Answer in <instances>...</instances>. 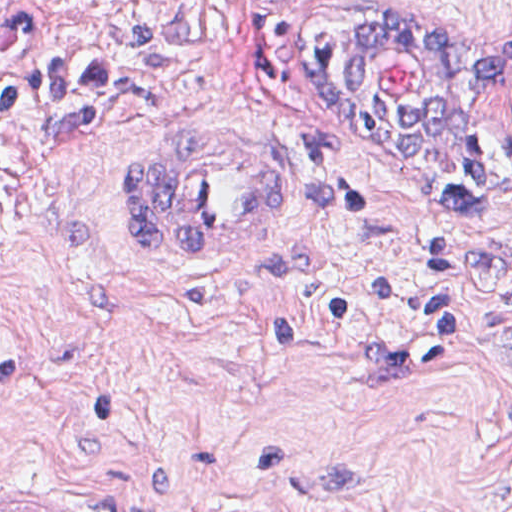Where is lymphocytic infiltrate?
<instances>
[{
  "label": "lymphocytic infiltrate",
  "mask_w": 512,
  "mask_h": 512,
  "mask_svg": "<svg viewBox=\"0 0 512 512\" xmlns=\"http://www.w3.org/2000/svg\"><path fill=\"white\" fill-rule=\"evenodd\" d=\"M41 1L24 0L0 29V156L20 112L97 98L126 80L118 65L47 50L40 37ZM443 158L457 207L512 231V130L475 134Z\"/></svg>",
  "instance_id": "lymphocytic-infiltrate-1"
}]
</instances>
